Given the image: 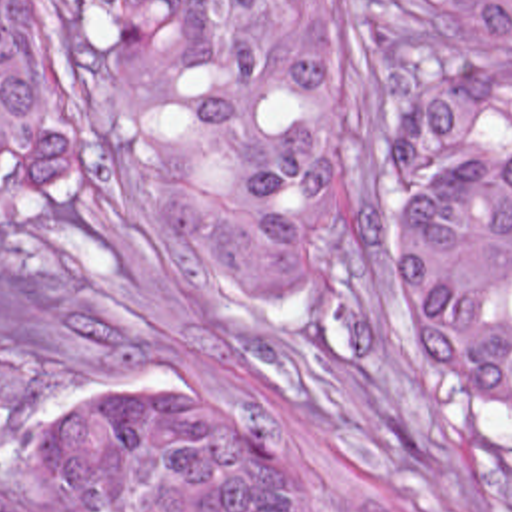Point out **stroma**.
<instances>
[{
	"instance_id": "stroma-1",
	"label": "stroma",
	"mask_w": 512,
	"mask_h": 512,
	"mask_svg": "<svg viewBox=\"0 0 512 512\" xmlns=\"http://www.w3.org/2000/svg\"><path fill=\"white\" fill-rule=\"evenodd\" d=\"M53 134L57 192L0 218V512H45V433L71 393L165 377L223 395L305 471L315 512H512V415L452 379L420 329L414 208L387 126L416 92L510 50L418 0H337L341 293L255 313L141 176L133 108L65 0H11Z\"/></svg>"
}]
</instances>
